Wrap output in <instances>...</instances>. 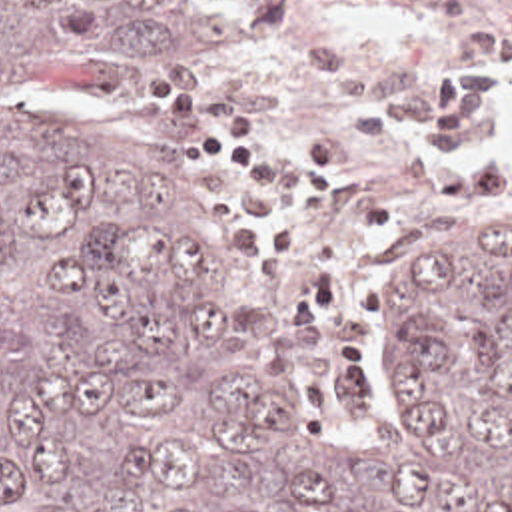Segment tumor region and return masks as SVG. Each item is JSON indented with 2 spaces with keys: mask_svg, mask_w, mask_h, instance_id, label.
<instances>
[{
  "mask_svg": "<svg viewBox=\"0 0 512 512\" xmlns=\"http://www.w3.org/2000/svg\"><path fill=\"white\" fill-rule=\"evenodd\" d=\"M232 40L208 0H0V512H512V238H430L342 453L200 206L29 98Z\"/></svg>",
  "mask_w": 512,
  "mask_h": 512,
  "instance_id": "obj_1",
  "label": "tumor region"
}]
</instances>
